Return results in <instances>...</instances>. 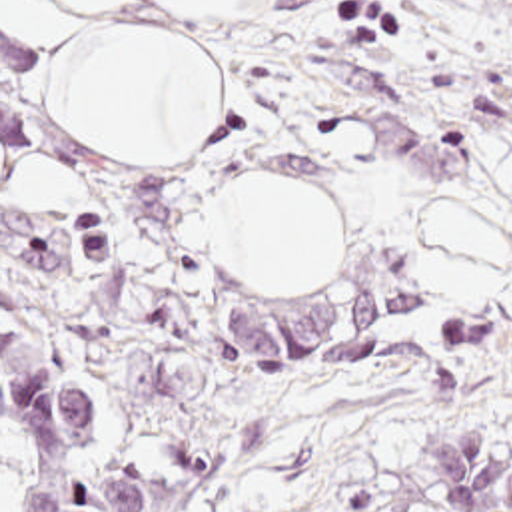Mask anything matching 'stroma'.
<instances>
[{
    "label": "stroma",
    "mask_w": 512,
    "mask_h": 512,
    "mask_svg": "<svg viewBox=\"0 0 512 512\" xmlns=\"http://www.w3.org/2000/svg\"><path fill=\"white\" fill-rule=\"evenodd\" d=\"M218 81V123L152 157L190 512H433L413 478L421 428L512 438V0H232L188 15L136 1ZM297 173L337 207L329 281H252L214 251L212 203L240 175ZM479 197L505 233L489 303H459L425 267L419 213ZM393 279L385 359L323 377L254 373L230 305ZM509 323L451 349L441 317Z\"/></svg>",
    "instance_id": "35a3bbf8"
}]
</instances>
